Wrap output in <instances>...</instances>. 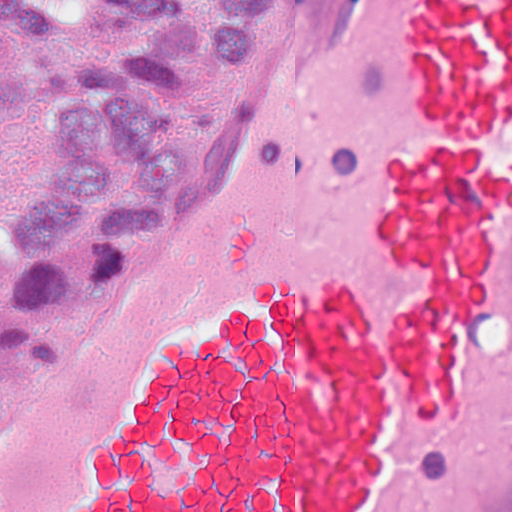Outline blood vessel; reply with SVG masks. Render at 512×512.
<instances>
[{
	"label": "blood vessel",
	"instance_id": "1",
	"mask_svg": "<svg viewBox=\"0 0 512 512\" xmlns=\"http://www.w3.org/2000/svg\"><path fill=\"white\" fill-rule=\"evenodd\" d=\"M0 512H512V0H300L179 218L0 341Z\"/></svg>",
	"mask_w": 512,
	"mask_h": 512
}]
</instances>
